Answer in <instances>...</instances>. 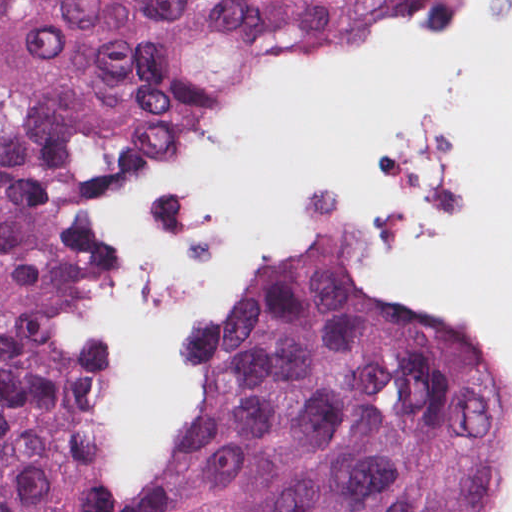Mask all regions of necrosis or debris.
Masks as SVG:
<instances>
[{
    "instance_id": "1",
    "label": "necrosis or debris",
    "mask_w": 512,
    "mask_h": 512,
    "mask_svg": "<svg viewBox=\"0 0 512 512\" xmlns=\"http://www.w3.org/2000/svg\"><path fill=\"white\" fill-rule=\"evenodd\" d=\"M474 512H512V426L491 446Z\"/></svg>"
}]
</instances>
